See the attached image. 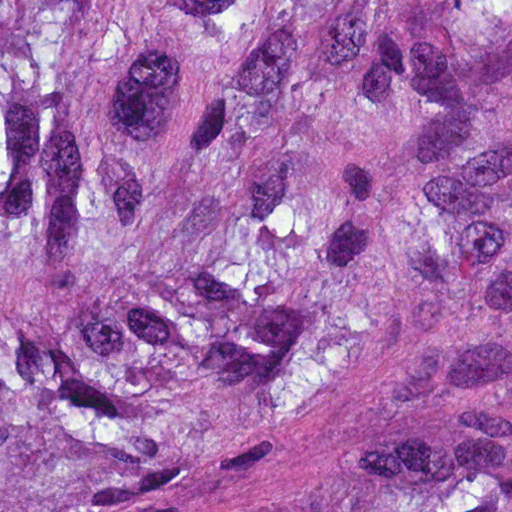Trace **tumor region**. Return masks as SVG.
Instances as JSON below:
<instances>
[{
    "mask_svg": "<svg viewBox=\"0 0 512 512\" xmlns=\"http://www.w3.org/2000/svg\"><path fill=\"white\" fill-rule=\"evenodd\" d=\"M0 512H512V0H0Z\"/></svg>",
    "mask_w": 512,
    "mask_h": 512,
    "instance_id": "1",
    "label": "tumor region"
}]
</instances>
